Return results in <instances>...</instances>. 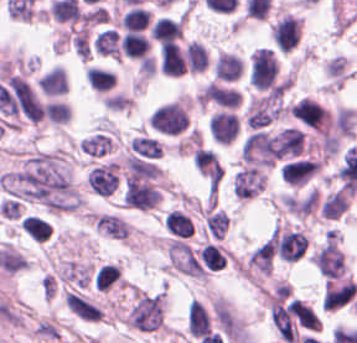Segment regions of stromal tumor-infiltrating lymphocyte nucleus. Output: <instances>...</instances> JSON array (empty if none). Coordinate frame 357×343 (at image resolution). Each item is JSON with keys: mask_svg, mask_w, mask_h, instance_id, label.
Instances as JSON below:
<instances>
[{"mask_svg": "<svg viewBox=\"0 0 357 343\" xmlns=\"http://www.w3.org/2000/svg\"><path fill=\"white\" fill-rule=\"evenodd\" d=\"M22 229L33 241L43 242L50 238L51 224L38 216L26 215L22 220Z\"/></svg>", "mask_w": 357, "mask_h": 343, "instance_id": "8", "label": "stromal tumor-infiltrating lymphocyte nucleus"}, {"mask_svg": "<svg viewBox=\"0 0 357 343\" xmlns=\"http://www.w3.org/2000/svg\"><path fill=\"white\" fill-rule=\"evenodd\" d=\"M290 114L307 127L321 132L329 123L328 113L309 97H302L290 107Z\"/></svg>", "mask_w": 357, "mask_h": 343, "instance_id": "2", "label": "stromal tumor-infiltrating lymphocyte nucleus"}, {"mask_svg": "<svg viewBox=\"0 0 357 343\" xmlns=\"http://www.w3.org/2000/svg\"><path fill=\"white\" fill-rule=\"evenodd\" d=\"M150 32L152 39L161 44L178 39L183 34L182 19L158 18L153 22Z\"/></svg>", "mask_w": 357, "mask_h": 343, "instance_id": "7", "label": "stromal tumor-infiltrating lymphocyte nucleus"}, {"mask_svg": "<svg viewBox=\"0 0 357 343\" xmlns=\"http://www.w3.org/2000/svg\"><path fill=\"white\" fill-rule=\"evenodd\" d=\"M165 226L177 236H190L194 227L190 218L183 212L171 210L164 218Z\"/></svg>", "mask_w": 357, "mask_h": 343, "instance_id": "10", "label": "stromal tumor-infiltrating lymphocyte nucleus"}, {"mask_svg": "<svg viewBox=\"0 0 357 343\" xmlns=\"http://www.w3.org/2000/svg\"><path fill=\"white\" fill-rule=\"evenodd\" d=\"M124 30H143L149 22L148 9L139 6H132L127 10L122 18Z\"/></svg>", "mask_w": 357, "mask_h": 343, "instance_id": "12", "label": "stromal tumor-infiltrating lymphocyte nucleus"}, {"mask_svg": "<svg viewBox=\"0 0 357 343\" xmlns=\"http://www.w3.org/2000/svg\"><path fill=\"white\" fill-rule=\"evenodd\" d=\"M321 164L319 158H297L288 161L281 167L282 178L286 183L306 184Z\"/></svg>", "mask_w": 357, "mask_h": 343, "instance_id": "3", "label": "stromal tumor-infiltrating lymphocyte nucleus"}, {"mask_svg": "<svg viewBox=\"0 0 357 343\" xmlns=\"http://www.w3.org/2000/svg\"><path fill=\"white\" fill-rule=\"evenodd\" d=\"M184 69V55L180 46L172 42H164L159 51V70L161 74L179 77Z\"/></svg>", "mask_w": 357, "mask_h": 343, "instance_id": "5", "label": "stromal tumor-infiltrating lymphocyte nucleus"}, {"mask_svg": "<svg viewBox=\"0 0 357 343\" xmlns=\"http://www.w3.org/2000/svg\"><path fill=\"white\" fill-rule=\"evenodd\" d=\"M302 37V22L293 16L277 17L270 26L271 44L279 54L297 49Z\"/></svg>", "mask_w": 357, "mask_h": 343, "instance_id": "1", "label": "stromal tumor-infiltrating lymphocyte nucleus"}, {"mask_svg": "<svg viewBox=\"0 0 357 343\" xmlns=\"http://www.w3.org/2000/svg\"><path fill=\"white\" fill-rule=\"evenodd\" d=\"M150 41L141 32L129 31L119 42L121 54L128 59L144 60L150 49Z\"/></svg>", "mask_w": 357, "mask_h": 343, "instance_id": "6", "label": "stromal tumor-infiltrating lymphocyte nucleus"}, {"mask_svg": "<svg viewBox=\"0 0 357 343\" xmlns=\"http://www.w3.org/2000/svg\"><path fill=\"white\" fill-rule=\"evenodd\" d=\"M86 76L90 87L96 92H107L115 85V71L90 66Z\"/></svg>", "mask_w": 357, "mask_h": 343, "instance_id": "9", "label": "stromal tumor-infiltrating lymphocyte nucleus"}, {"mask_svg": "<svg viewBox=\"0 0 357 343\" xmlns=\"http://www.w3.org/2000/svg\"><path fill=\"white\" fill-rule=\"evenodd\" d=\"M198 255L204 266L215 271L224 266L227 259L220 245L214 242H207Z\"/></svg>", "mask_w": 357, "mask_h": 343, "instance_id": "11", "label": "stromal tumor-infiltrating lymphocyte nucleus"}, {"mask_svg": "<svg viewBox=\"0 0 357 343\" xmlns=\"http://www.w3.org/2000/svg\"><path fill=\"white\" fill-rule=\"evenodd\" d=\"M91 280L96 291L104 293L122 288L123 285L121 269L112 262L95 266Z\"/></svg>", "mask_w": 357, "mask_h": 343, "instance_id": "4", "label": "stromal tumor-infiltrating lymphocyte nucleus"}]
</instances>
